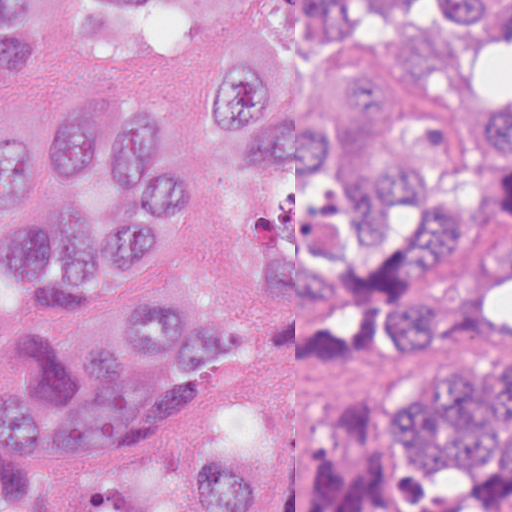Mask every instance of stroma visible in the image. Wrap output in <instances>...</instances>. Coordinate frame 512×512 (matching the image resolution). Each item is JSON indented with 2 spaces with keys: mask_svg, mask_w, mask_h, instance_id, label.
Returning <instances> with one entry per match:
<instances>
[{
  "mask_svg": "<svg viewBox=\"0 0 512 512\" xmlns=\"http://www.w3.org/2000/svg\"><path fill=\"white\" fill-rule=\"evenodd\" d=\"M463 97L512 93V39L463 49L443 60ZM130 76L150 85L172 124L190 141L194 171L177 208L181 231L206 268L242 298L254 324L242 364L206 398L164 420L125 455L65 459L1 453L32 465L40 486L77 512L106 493L147 481L163 489L185 480L211 445L256 449L260 494L245 512H287L289 468L312 432L336 421L367 419L376 397L411 367L462 353H512L496 331L446 335L428 348L365 351L347 360L304 357L271 324L261 288L265 265L244 229L226 141L208 138L197 117L201 56L185 65H138L98 56L82 43L79 0H48L15 62L0 70V137L36 133L77 104L83 84Z\"/></svg>",
  "mask_w": 512,
  "mask_h": 512,
  "instance_id": "1",
  "label": "stroma"
}]
</instances>
